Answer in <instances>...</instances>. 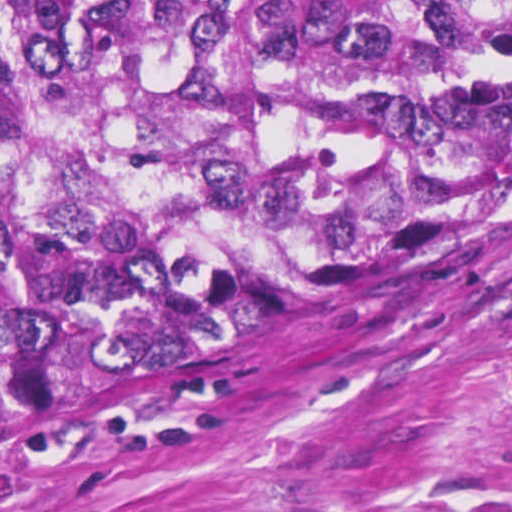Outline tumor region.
<instances>
[{
  "label": "tumor region",
  "mask_w": 512,
  "mask_h": 512,
  "mask_svg": "<svg viewBox=\"0 0 512 512\" xmlns=\"http://www.w3.org/2000/svg\"><path fill=\"white\" fill-rule=\"evenodd\" d=\"M512 196V0H0V449Z\"/></svg>",
  "instance_id": "1"
}]
</instances>
